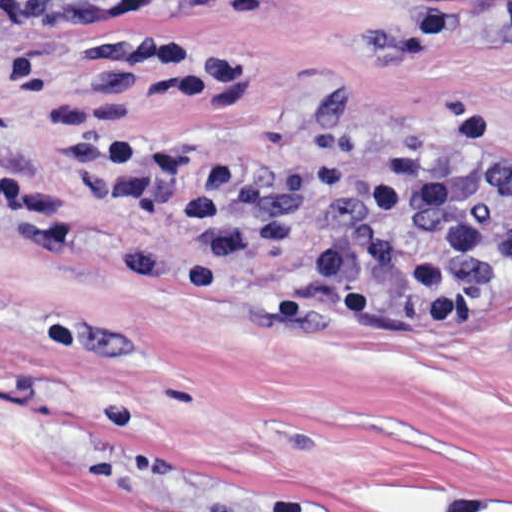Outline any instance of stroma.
<instances>
[{
    "mask_svg": "<svg viewBox=\"0 0 512 512\" xmlns=\"http://www.w3.org/2000/svg\"><path fill=\"white\" fill-rule=\"evenodd\" d=\"M97 35L240 57L232 93L132 106L153 136L302 158L352 90L382 135L489 107L512 157V0H0V169L69 235L0 231V512H512V277L479 324L400 330L278 326L272 262L231 299L133 278L175 226L77 188L54 128Z\"/></svg>",
    "mask_w": 512,
    "mask_h": 512,
    "instance_id": "35a3bbf8",
    "label": "stroma"
}]
</instances>
